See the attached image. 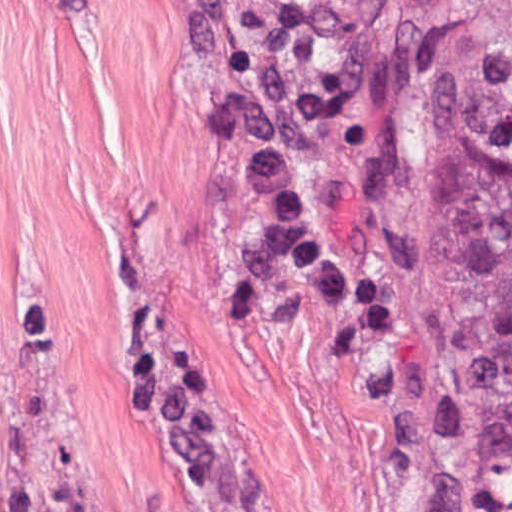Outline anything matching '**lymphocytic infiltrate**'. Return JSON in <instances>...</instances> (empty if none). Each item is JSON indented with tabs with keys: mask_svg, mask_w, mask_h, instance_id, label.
Instances as JSON below:
<instances>
[{
	"mask_svg": "<svg viewBox=\"0 0 512 512\" xmlns=\"http://www.w3.org/2000/svg\"><path fill=\"white\" fill-rule=\"evenodd\" d=\"M254 12L275 22H286L311 0H243Z\"/></svg>",
	"mask_w": 512,
	"mask_h": 512,
	"instance_id": "1",
	"label": "lymphocytic infiltrate"
}]
</instances>
